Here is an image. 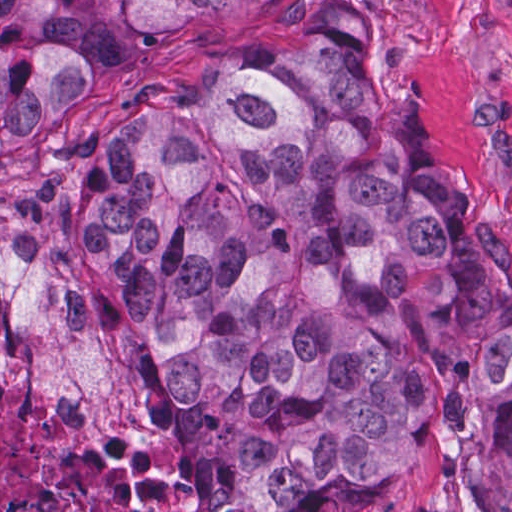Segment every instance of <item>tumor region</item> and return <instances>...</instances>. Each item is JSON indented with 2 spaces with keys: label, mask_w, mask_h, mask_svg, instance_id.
I'll list each match as a JSON object with an SVG mask.
<instances>
[{
  "label": "tumor region",
  "mask_w": 512,
  "mask_h": 512,
  "mask_svg": "<svg viewBox=\"0 0 512 512\" xmlns=\"http://www.w3.org/2000/svg\"><path fill=\"white\" fill-rule=\"evenodd\" d=\"M234 1H0V157ZM102 137L68 234L206 512H329L428 453L512 510V258L443 181L384 37L317 25Z\"/></svg>",
  "instance_id": "obj_1"
}]
</instances>
